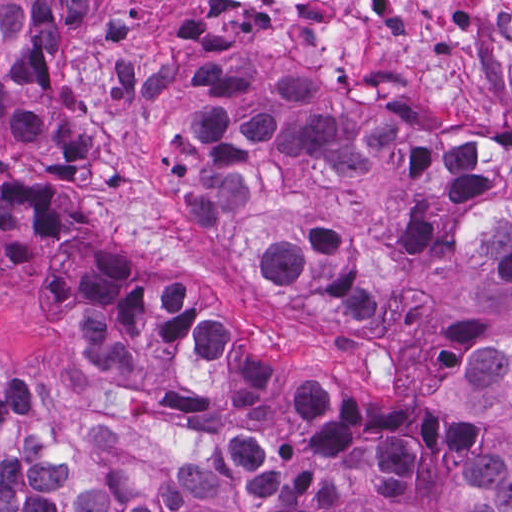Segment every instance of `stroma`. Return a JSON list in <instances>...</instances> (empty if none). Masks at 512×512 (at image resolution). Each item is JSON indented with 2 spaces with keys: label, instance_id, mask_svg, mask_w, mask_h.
<instances>
[{
  "label": "stroma",
  "instance_id": "1",
  "mask_svg": "<svg viewBox=\"0 0 512 512\" xmlns=\"http://www.w3.org/2000/svg\"><path fill=\"white\" fill-rule=\"evenodd\" d=\"M500 33L510 65L512 10ZM280 27L228 0H92L70 50V94L85 153L73 205L34 239L0 242V382L29 393L79 434L104 435L168 461L220 453L221 421L176 411L160 394L96 379L40 339L42 293L98 253L124 282L198 301L204 323L226 324L282 384L349 375L369 412L415 408L465 424L473 441L312 456L343 477L368 478L405 457L474 454L484 430L455 399L472 361L512 350V297L465 284L418 290L389 318L365 317L324 293L279 290L244 259L221 252L181 201L160 147L177 78L220 59L261 67L308 137L397 147L424 177L512 168V144L485 134L431 131L386 102L283 62Z\"/></svg>",
  "mask_w": 512,
  "mask_h": 512
}]
</instances>
